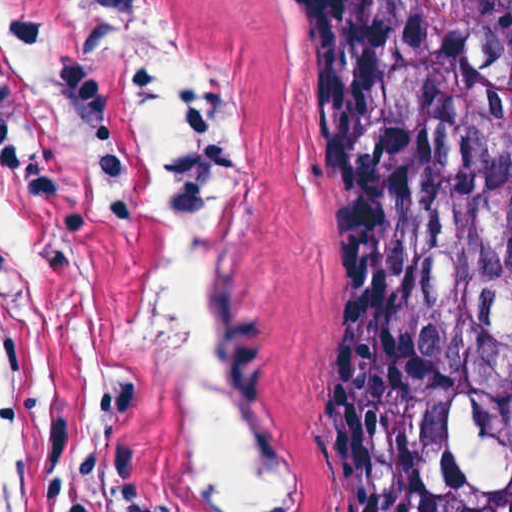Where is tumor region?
Here are the masks:
<instances>
[{"mask_svg": "<svg viewBox=\"0 0 512 512\" xmlns=\"http://www.w3.org/2000/svg\"><path fill=\"white\" fill-rule=\"evenodd\" d=\"M321 98L335 512H512V0H295Z\"/></svg>", "mask_w": 512, "mask_h": 512, "instance_id": "obj_1", "label": "tumor region"}]
</instances>
